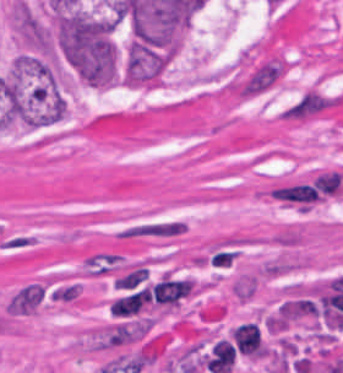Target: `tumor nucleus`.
Returning a JSON list of instances; mask_svg holds the SVG:
<instances>
[{
	"label": "tumor nucleus",
	"instance_id": "tumor-nucleus-1",
	"mask_svg": "<svg viewBox=\"0 0 343 373\" xmlns=\"http://www.w3.org/2000/svg\"><path fill=\"white\" fill-rule=\"evenodd\" d=\"M54 36L59 54L81 81L106 87L117 78L114 17L68 11L58 17Z\"/></svg>",
	"mask_w": 343,
	"mask_h": 373
},
{
	"label": "tumor nucleus",
	"instance_id": "tumor-nucleus-2",
	"mask_svg": "<svg viewBox=\"0 0 343 373\" xmlns=\"http://www.w3.org/2000/svg\"><path fill=\"white\" fill-rule=\"evenodd\" d=\"M14 24L26 45L37 50H48V28L21 0L14 4Z\"/></svg>",
	"mask_w": 343,
	"mask_h": 373
}]
</instances>
